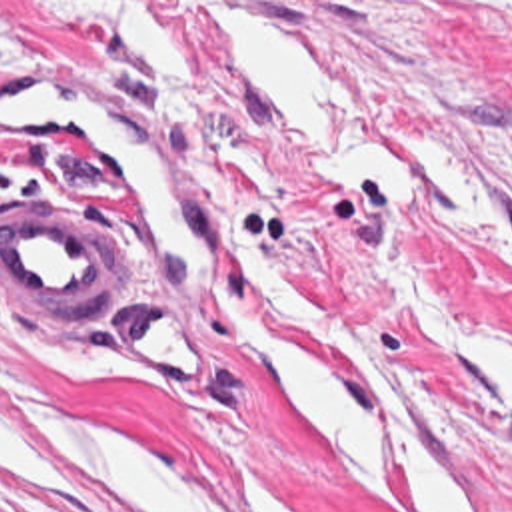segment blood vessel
Instances as JSON below:
<instances>
[{"label":"blood vessel","instance_id":"1","mask_svg":"<svg viewBox=\"0 0 512 512\" xmlns=\"http://www.w3.org/2000/svg\"><path fill=\"white\" fill-rule=\"evenodd\" d=\"M116 94L0 78V118L75 148L116 190L160 284L200 288L220 252L222 220L164 136ZM114 234L75 204H41L0 220L7 305H87L109 296ZM126 353L168 381H206L210 349L180 307L142 299L112 321Z\"/></svg>","mask_w":512,"mask_h":512}]
</instances>
